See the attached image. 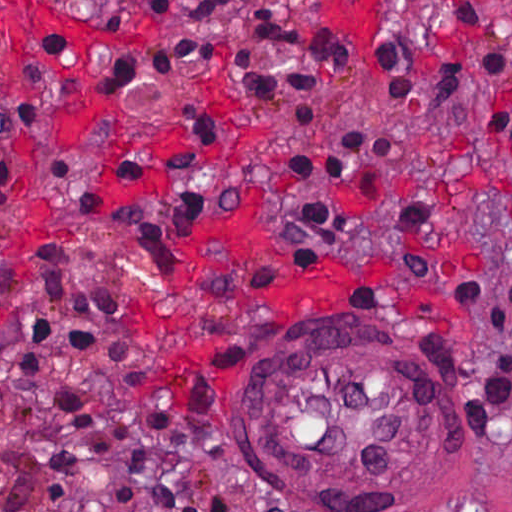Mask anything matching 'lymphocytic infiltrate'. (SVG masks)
I'll use <instances>...</instances> for the list:
<instances>
[{
  "instance_id": "1",
  "label": "lymphocytic infiltrate",
  "mask_w": 512,
  "mask_h": 512,
  "mask_svg": "<svg viewBox=\"0 0 512 512\" xmlns=\"http://www.w3.org/2000/svg\"><path fill=\"white\" fill-rule=\"evenodd\" d=\"M459 25L449 73L431 88L435 110L458 82L477 74L475 107L486 133L512 150V60L489 24L481 0H442ZM284 0H156L152 24L171 31L165 49L121 57L94 84L102 92L154 93L167 76L203 70L220 60L218 48L190 42L179 31L212 22L232 23L249 42L287 49L288 66L266 68L238 56L248 93L261 103L285 92L295 101L290 120L308 128L318 104L316 83L349 71L350 45L336 28H293L280 10ZM390 105L410 101L414 56L399 40L379 37L369 47ZM40 123V104L10 107L0 115V141L25 142ZM184 140L163 160L167 189L142 190L145 158L119 152L112 177L126 192L107 201L95 184L66 159L53 160V174L77 216L122 235L152 268L175 252L218 203V146L207 117L197 107L181 114ZM397 136L385 126L346 131L334 144L290 161L296 178L342 183L367 167L389 161ZM16 206V175L0 164V222ZM292 228L353 258L364 247L335 199L305 200L278 216ZM38 299L59 315L50 320L27 311L7 337L57 338L84 345L102 314L122 306L131 293L76 280L61 238L29 244ZM0 429L34 445L32 480L16 512H74L90 475L103 467L131 488L138 512H203V468L196 452L152 410L80 370L40 354L0 351Z\"/></svg>"
}]
</instances>
